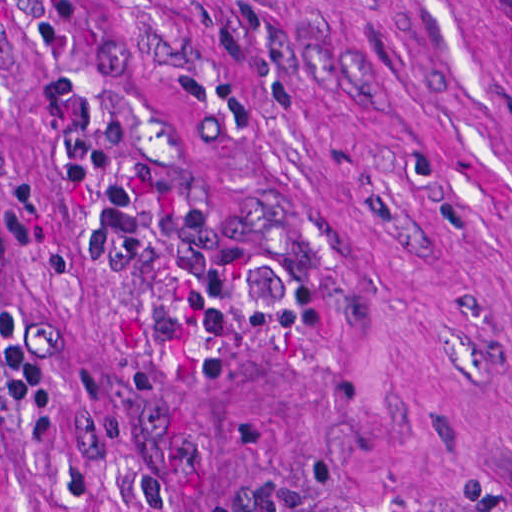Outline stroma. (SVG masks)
<instances>
[{
	"label": "stroma",
	"mask_w": 512,
	"mask_h": 512,
	"mask_svg": "<svg viewBox=\"0 0 512 512\" xmlns=\"http://www.w3.org/2000/svg\"><path fill=\"white\" fill-rule=\"evenodd\" d=\"M0 512H512V0H0Z\"/></svg>",
	"instance_id": "obj_1"
}]
</instances>
